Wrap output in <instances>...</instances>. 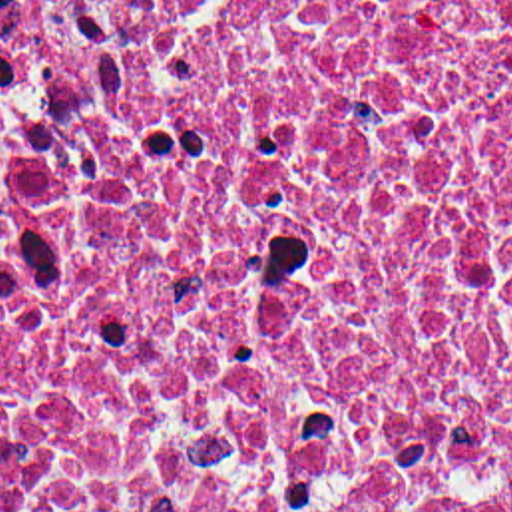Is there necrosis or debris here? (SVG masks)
<instances>
[{
	"instance_id": "obj_1",
	"label": "necrosis or debris",
	"mask_w": 512,
	"mask_h": 512,
	"mask_svg": "<svg viewBox=\"0 0 512 512\" xmlns=\"http://www.w3.org/2000/svg\"><path fill=\"white\" fill-rule=\"evenodd\" d=\"M0 512H512V0H0Z\"/></svg>"
}]
</instances>
